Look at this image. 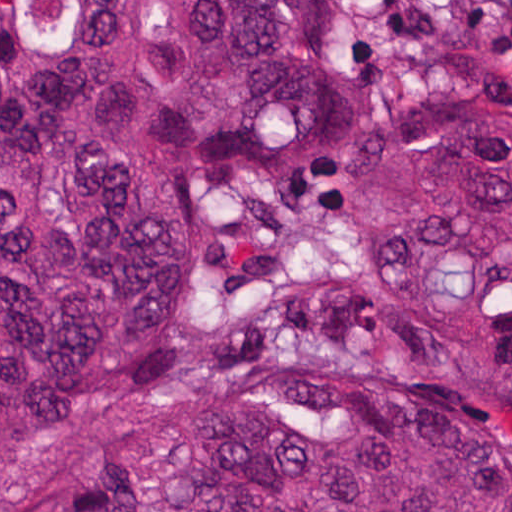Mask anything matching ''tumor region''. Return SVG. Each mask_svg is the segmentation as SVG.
I'll return each instance as SVG.
<instances>
[{
	"label": "tumor region",
	"instance_id": "tumor-region-1",
	"mask_svg": "<svg viewBox=\"0 0 512 512\" xmlns=\"http://www.w3.org/2000/svg\"><path fill=\"white\" fill-rule=\"evenodd\" d=\"M354 109L316 0H0V512H512V125L363 145L319 277L198 318Z\"/></svg>",
	"mask_w": 512,
	"mask_h": 512
}]
</instances>
